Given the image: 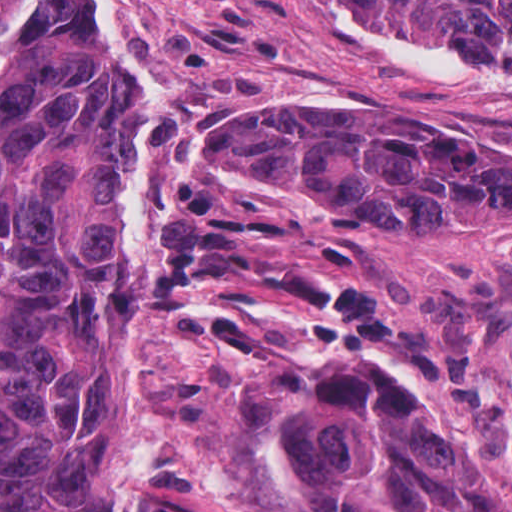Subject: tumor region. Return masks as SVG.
Returning <instances> with one entry per match:
<instances>
[{
  "instance_id": "tumor-region-1",
  "label": "tumor region",
  "mask_w": 512,
  "mask_h": 512,
  "mask_svg": "<svg viewBox=\"0 0 512 512\" xmlns=\"http://www.w3.org/2000/svg\"><path fill=\"white\" fill-rule=\"evenodd\" d=\"M512 40V0H388ZM138 69L74 0H26L0 75V512H141L110 481L99 412L112 342L146 320L158 254L128 249ZM197 170L267 180L346 224L482 238L512 224V150L435 141L381 108L264 105L182 127ZM258 476L284 512H512V344L477 332L407 387L314 355L226 297Z\"/></svg>"
}]
</instances>
